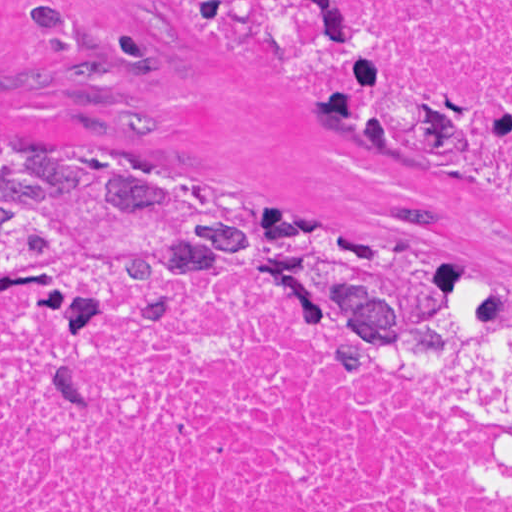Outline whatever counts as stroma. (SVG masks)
I'll list each match as a JSON object with an SVG mask.
<instances>
[{"label": "stroma", "instance_id": "35a3bbf8", "mask_svg": "<svg viewBox=\"0 0 512 512\" xmlns=\"http://www.w3.org/2000/svg\"><path fill=\"white\" fill-rule=\"evenodd\" d=\"M341 2L402 84L477 106L463 154L342 141L323 84L179 0H0V146H41L195 206L383 240L495 283L512 311V207L464 178L501 158L512 113L394 58L366 1Z\"/></svg>", "mask_w": 512, "mask_h": 512}]
</instances>
